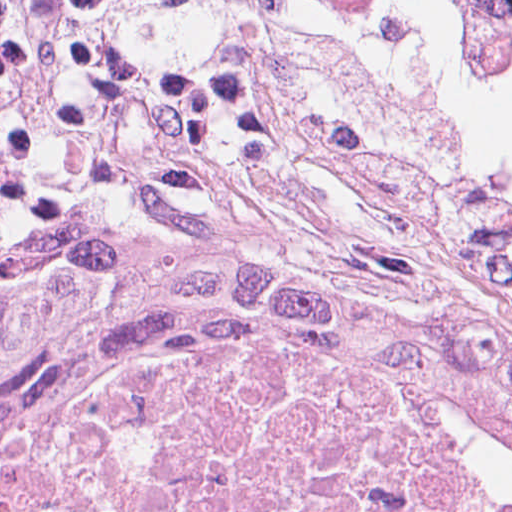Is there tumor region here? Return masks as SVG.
<instances>
[{
    "mask_svg": "<svg viewBox=\"0 0 512 512\" xmlns=\"http://www.w3.org/2000/svg\"><path fill=\"white\" fill-rule=\"evenodd\" d=\"M153 11L313 0H132ZM512 54V0H448ZM118 334L512 397V319L420 227H237L0 264V372Z\"/></svg>",
    "mask_w": 512,
    "mask_h": 512,
    "instance_id": "obj_1",
    "label": "tumor region"
}]
</instances>
